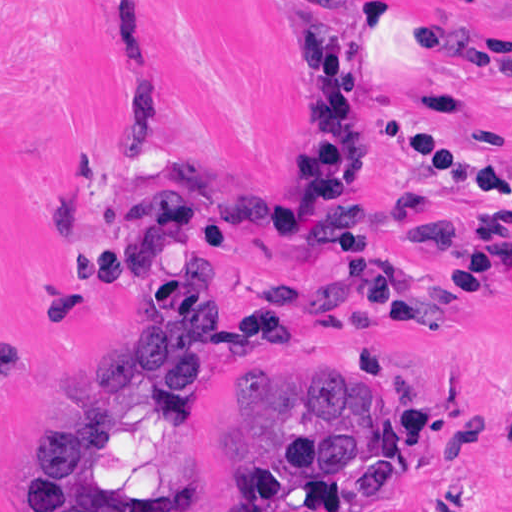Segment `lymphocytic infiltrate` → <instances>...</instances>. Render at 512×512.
<instances>
[{
  "label": "lymphocytic infiltrate",
  "instance_id": "lymphocytic-infiltrate-1",
  "mask_svg": "<svg viewBox=\"0 0 512 512\" xmlns=\"http://www.w3.org/2000/svg\"><path fill=\"white\" fill-rule=\"evenodd\" d=\"M313 4L364 1L367 18L322 23L303 10L305 77L316 100V148L298 200L329 247L334 265L323 278H278L249 251L246 236H289V219L264 182L234 201L207 187L176 191L144 203L127 249L129 276L143 279L158 257L217 251L253 264L255 292L235 330L219 341L253 347L289 341L300 330L362 333L380 320L418 324L413 273L378 256L376 209L359 192L381 168L383 152L366 93L370 58L395 22L391 0H305ZM400 153L422 163L434 179L484 199L490 223L474 231L467 259L452 281L475 291L512 239V184L496 160L440 127L418 120Z\"/></svg>",
  "mask_w": 512,
  "mask_h": 512
}]
</instances>
